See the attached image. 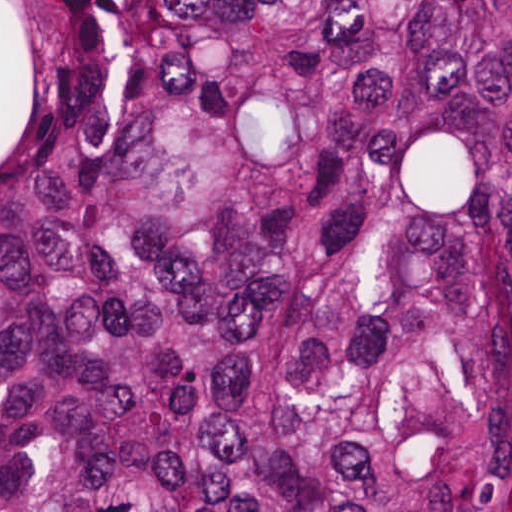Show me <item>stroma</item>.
Wrapping results in <instances>:
<instances>
[{
  "label": "stroma",
  "mask_w": 512,
  "mask_h": 512,
  "mask_svg": "<svg viewBox=\"0 0 512 512\" xmlns=\"http://www.w3.org/2000/svg\"><path fill=\"white\" fill-rule=\"evenodd\" d=\"M89 1H512V0H0V131L14 56L26 39Z\"/></svg>",
  "instance_id": "stroma-1"
}]
</instances>
